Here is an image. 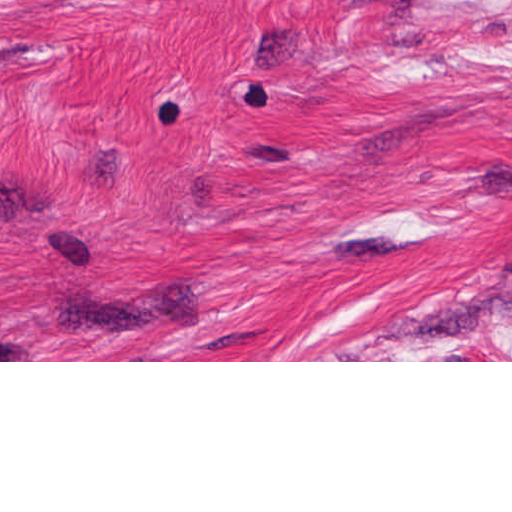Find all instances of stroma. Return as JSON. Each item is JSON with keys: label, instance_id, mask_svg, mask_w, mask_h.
<instances>
[{"label": "stroma", "instance_id": "1", "mask_svg": "<svg viewBox=\"0 0 512 512\" xmlns=\"http://www.w3.org/2000/svg\"><path fill=\"white\" fill-rule=\"evenodd\" d=\"M0 362H512V0H0Z\"/></svg>", "mask_w": 512, "mask_h": 512}]
</instances>
